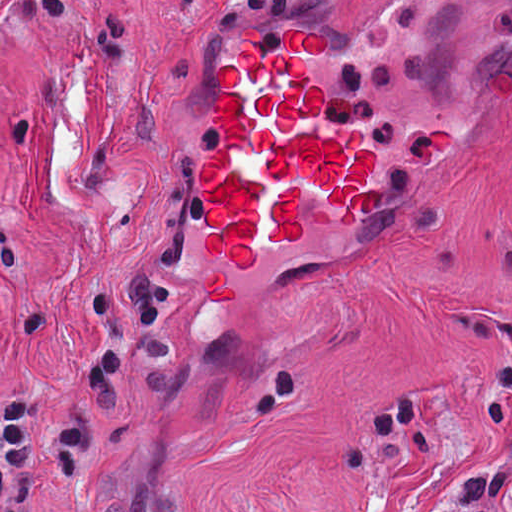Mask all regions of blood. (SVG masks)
<instances>
[{"label":"blood","instance_id":"1","mask_svg":"<svg viewBox=\"0 0 512 512\" xmlns=\"http://www.w3.org/2000/svg\"><path fill=\"white\" fill-rule=\"evenodd\" d=\"M321 30L290 25L266 48L263 30L242 28L236 56L219 62L215 81L217 144L198 164L207 228L201 244L214 255V273L201 287L214 304H230L222 260L249 270L256 245L299 241L305 188L314 185L344 224L368 213L378 188L366 177L373 152L361 127L322 123L321 87L310 60L326 52Z\"/></svg>","mask_w":512,"mask_h":512}]
</instances>
